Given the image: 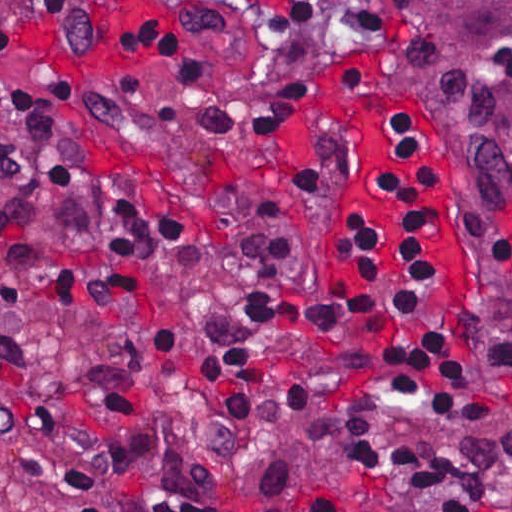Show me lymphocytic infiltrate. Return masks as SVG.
<instances>
[{
	"instance_id": "obj_1",
	"label": "lymphocytic infiltrate",
	"mask_w": 512,
	"mask_h": 512,
	"mask_svg": "<svg viewBox=\"0 0 512 512\" xmlns=\"http://www.w3.org/2000/svg\"><path fill=\"white\" fill-rule=\"evenodd\" d=\"M238 43L280 44L266 80H227L200 43L166 27L128 31V51L186 91L202 132L250 139L298 133L287 185L332 194L343 175L337 131L308 117L325 60L343 48L333 0H173ZM102 0H0V49L36 26L71 54L93 52ZM78 110L76 81L46 92L0 82V266L77 310L120 342L94 415L64 421L41 362L12 333L0 340V441L54 461L51 512H387L374 496L330 490L271 499L243 480L247 458L298 416L405 405L450 421L481 405L469 319L475 246L436 210L394 146L371 173L403 241L385 261L370 214L341 231L355 291L298 304L306 272L299 220L261 191L230 208L226 246L208 248L165 187L106 173L55 126Z\"/></svg>"
}]
</instances>
